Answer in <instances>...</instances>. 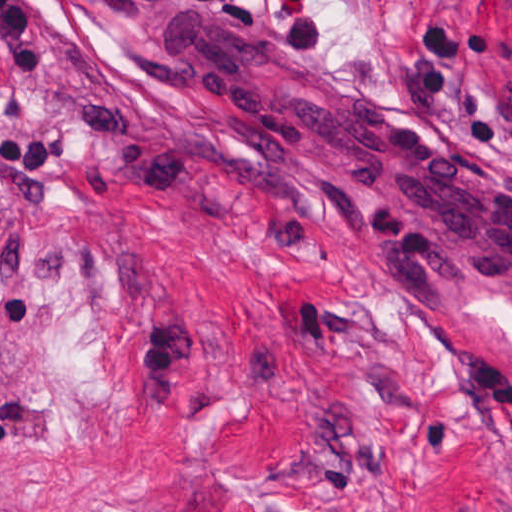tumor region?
<instances>
[{"instance_id":"obj_1","label":"tumor region","mask_w":512,"mask_h":512,"mask_svg":"<svg viewBox=\"0 0 512 512\" xmlns=\"http://www.w3.org/2000/svg\"><path fill=\"white\" fill-rule=\"evenodd\" d=\"M125 33L137 72L160 93L181 90L166 81L141 55L137 30L146 15L189 12L213 25L239 45L282 71L311 81L333 93L369 106L294 62L260 36L235 0H99ZM206 172L258 206H314L339 217L352 231L376 247L398 268L418 303L432 316H454L457 285L483 281L444 261L414 242L391 234L363 212L348 205L336 192L310 180L273 153L241 136L215 114L212 142L205 152Z\"/></svg>"}]
</instances>
